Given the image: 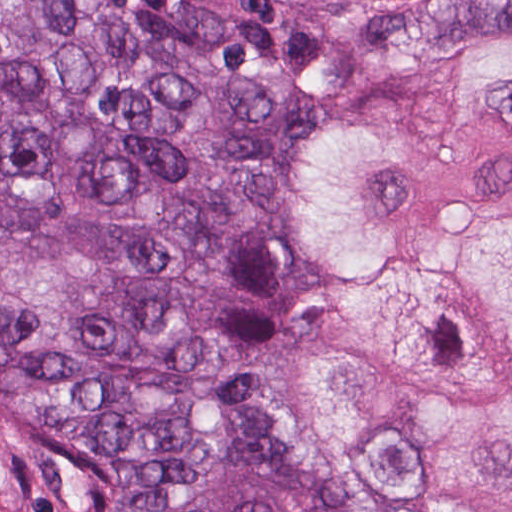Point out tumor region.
I'll return each mask as SVG.
<instances>
[{
    "label": "tumor region",
    "mask_w": 512,
    "mask_h": 512,
    "mask_svg": "<svg viewBox=\"0 0 512 512\" xmlns=\"http://www.w3.org/2000/svg\"><path fill=\"white\" fill-rule=\"evenodd\" d=\"M480 30L512 0L391 8L254 69L119 0L1 1V404L61 432L92 512H376L247 396L240 256L292 130ZM246 357L264 416L366 496L512 512V41L286 150Z\"/></svg>",
    "instance_id": "tumor-region-1"
}]
</instances>
